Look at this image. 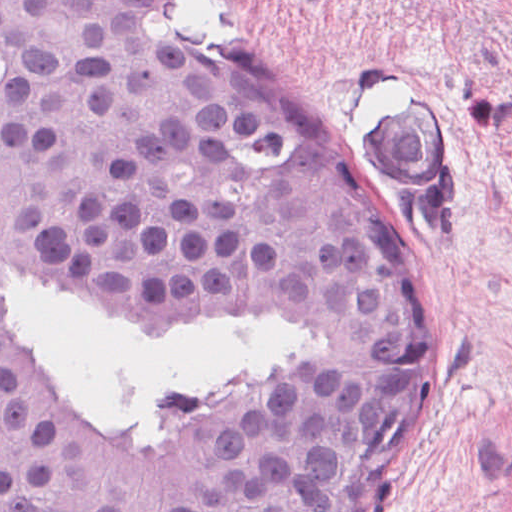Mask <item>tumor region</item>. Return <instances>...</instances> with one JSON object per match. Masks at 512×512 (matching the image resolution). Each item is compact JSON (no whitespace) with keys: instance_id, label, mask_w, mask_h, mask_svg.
<instances>
[{"instance_id":"1","label":"tumor region","mask_w":512,"mask_h":512,"mask_svg":"<svg viewBox=\"0 0 512 512\" xmlns=\"http://www.w3.org/2000/svg\"><path fill=\"white\" fill-rule=\"evenodd\" d=\"M177 0H0V265L111 307L254 303L374 373L415 369L402 229L354 170L189 46ZM399 200L435 180L407 89L370 132ZM371 405L295 379L186 430L70 407L0 305V512H356Z\"/></svg>"}]
</instances>
